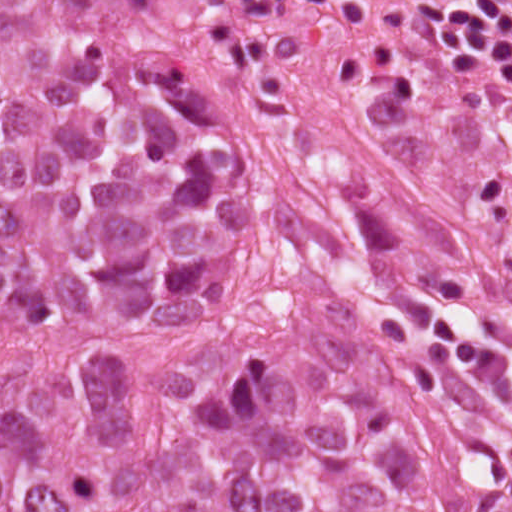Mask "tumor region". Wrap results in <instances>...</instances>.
Returning a JSON list of instances; mask_svg holds the SVG:
<instances>
[{
    "label": "tumor region",
    "mask_w": 512,
    "mask_h": 512,
    "mask_svg": "<svg viewBox=\"0 0 512 512\" xmlns=\"http://www.w3.org/2000/svg\"><path fill=\"white\" fill-rule=\"evenodd\" d=\"M217 74L178 0H0V512H512V332Z\"/></svg>",
    "instance_id": "1"
}]
</instances>
